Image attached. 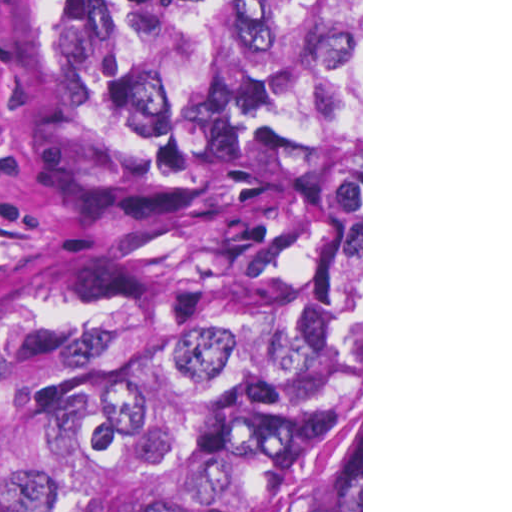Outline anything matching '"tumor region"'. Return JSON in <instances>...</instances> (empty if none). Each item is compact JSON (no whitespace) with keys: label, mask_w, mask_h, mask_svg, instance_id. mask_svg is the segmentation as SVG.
<instances>
[{"label":"tumor region","mask_w":512,"mask_h":512,"mask_svg":"<svg viewBox=\"0 0 512 512\" xmlns=\"http://www.w3.org/2000/svg\"><path fill=\"white\" fill-rule=\"evenodd\" d=\"M22 112L133 207L0 264V512H361V0H13Z\"/></svg>","instance_id":"obj_1"}]
</instances>
